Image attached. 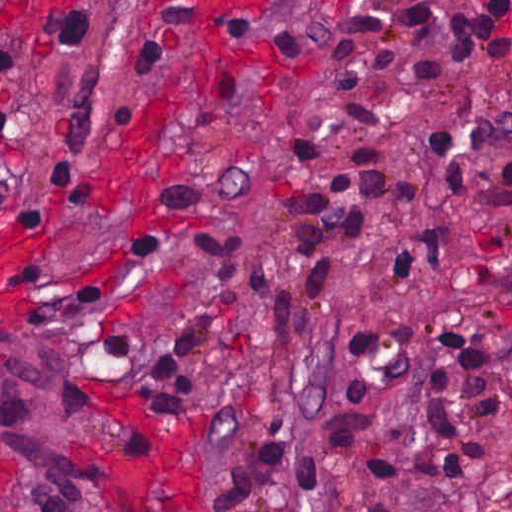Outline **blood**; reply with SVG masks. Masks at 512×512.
<instances>
[{"label": "blood", "mask_w": 512, "mask_h": 512, "mask_svg": "<svg viewBox=\"0 0 512 512\" xmlns=\"http://www.w3.org/2000/svg\"><path fill=\"white\" fill-rule=\"evenodd\" d=\"M193 1L202 9L208 27L199 41L183 51L160 103L141 114L128 131L125 144L103 165L106 185L118 193H126L152 172L173 131L176 99L185 77L196 65L223 60L229 45L223 28L231 13L246 0ZM336 1L347 10L359 7V0ZM492 1L477 0V3L485 5ZM498 32L512 36V13L503 18Z\"/></svg>", "instance_id": "obj_1"}]
</instances>
